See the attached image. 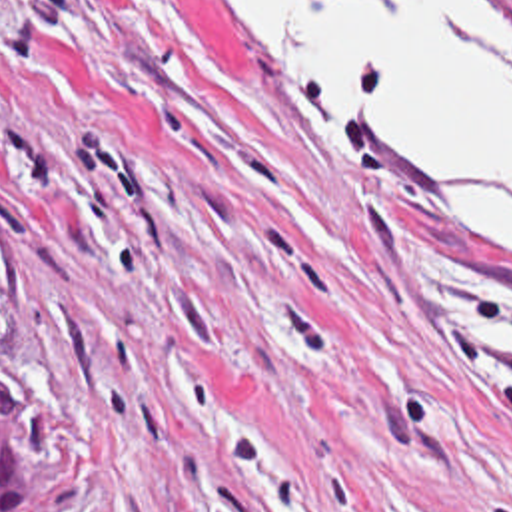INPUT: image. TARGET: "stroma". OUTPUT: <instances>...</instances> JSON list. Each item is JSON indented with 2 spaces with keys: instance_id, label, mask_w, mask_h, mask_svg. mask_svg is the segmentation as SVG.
<instances>
[{
  "instance_id": "stroma-1",
  "label": "stroma",
  "mask_w": 512,
  "mask_h": 512,
  "mask_svg": "<svg viewBox=\"0 0 512 512\" xmlns=\"http://www.w3.org/2000/svg\"><path fill=\"white\" fill-rule=\"evenodd\" d=\"M501 335L511 239L395 211L202 0H0V355L54 512H512Z\"/></svg>"
}]
</instances>
